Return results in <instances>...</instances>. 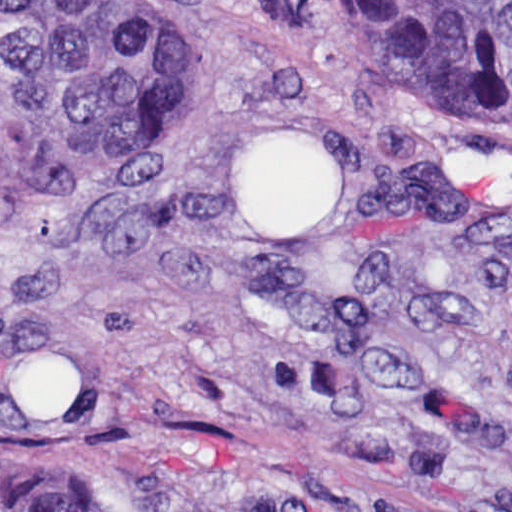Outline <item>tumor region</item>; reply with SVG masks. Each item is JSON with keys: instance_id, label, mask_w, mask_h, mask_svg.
I'll use <instances>...</instances> for the list:
<instances>
[{"instance_id": "1", "label": "tumor region", "mask_w": 512, "mask_h": 512, "mask_svg": "<svg viewBox=\"0 0 512 512\" xmlns=\"http://www.w3.org/2000/svg\"><path fill=\"white\" fill-rule=\"evenodd\" d=\"M441 113L512 129V0H317ZM166 72L117 0H1V189L115 148L162 105ZM1 512H308L265 480L227 491L146 464L104 502L73 481L1 491Z\"/></svg>"}]
</instances>
